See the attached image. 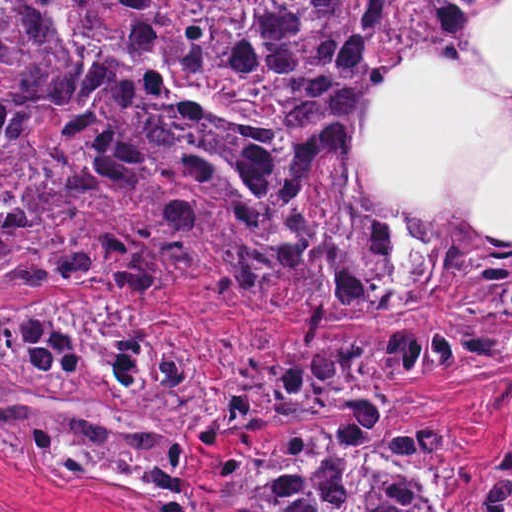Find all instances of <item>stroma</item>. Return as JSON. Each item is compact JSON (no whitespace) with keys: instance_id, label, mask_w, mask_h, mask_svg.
<instances>
[{"instance_id":"35a3bbf8","label":"stroma","mask_w":512,"mask_h":512,"mask_svg":"<svg viewBox=\"0 0 512 512\" xmlns=\"http://www.w3.org/2000/svg\"><path fill=\"white\" fill-rule=\"evenodd\" d=\"M1 1H500L470 28L467 55L476 71L494 85L512 89V0H0V512H150L121 504L83 485L57 490L31 480L1 464V305L21 299L42 305L53 301L109 300L137 310L142 316L171 319L184 326L189 345L206 369L216 374L221 362L200 348L215 338L235 343L252 332L276 335L273 346L256 354L267 364L293 347L324 341H353L382 354V363L413 396L395 418L434 424L458 460L469 470V484L440 501L445 512H484L476 495L487 482L497 455H512V369L493 375H438L412 378L391 363L389 347L362 341L408 331H373L344 336H297L276 322L247 319L235 303H192L145 300L127 291L44 290L1 294ZM391 421L383 417L381 426ZM366 424L340 417H272L229 448H199L192 462V492L208 512H223L213 469L228 455L254 462L329 425Z\"/></svg>"}]
</instances>
